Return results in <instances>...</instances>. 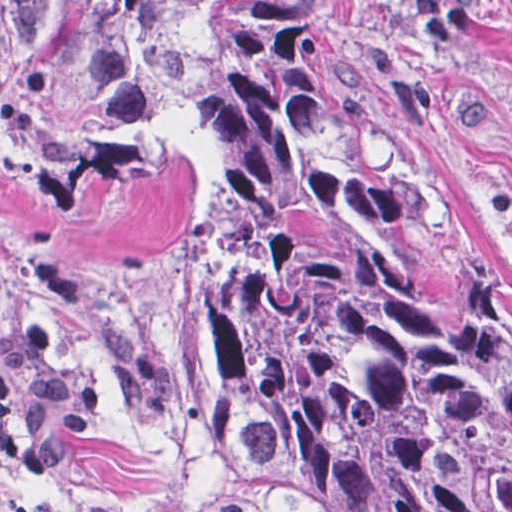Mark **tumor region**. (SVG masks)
Returning a JSON list of instances; mask_svg holds the SVG:
<instances>
[{"instance_id": "tumor-region-1", "label": "tumor region", "mask_w": 512, "mask_h": 512, "mask_svg": "<svg viewBox=\"0 0 512 512\" xmlns=\"http://www.w3.org/2000/svg\"><path fill=\"white\" fill-rule=\"evenodd\" d=\"M341 0L0 8V454L149 426L291 512H512V290L334 76Z\"/></svg>"}]
</instances>
